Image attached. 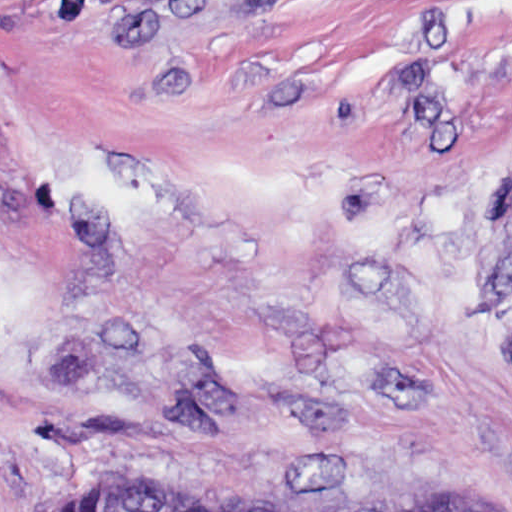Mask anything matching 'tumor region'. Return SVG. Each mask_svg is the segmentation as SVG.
<instances>
[{
	"mask_svg": "<svg viewBox=\"0 0 512 512\" xmlns=\"http://www.w3.org/2000/svg\"><path fill=\"white\" fill-rule=\"evenodd\" d=\"M19 512H216L185 486L131 477H102L67 495L45 497ZM421 512H504L494 495L482 489L446 492Z\"/></svg>",
	"mask_w": 512,
	"mask_h": 512,
	"instance_id": "obj_1",
	"label": "tumor region"
}]
</instances>
